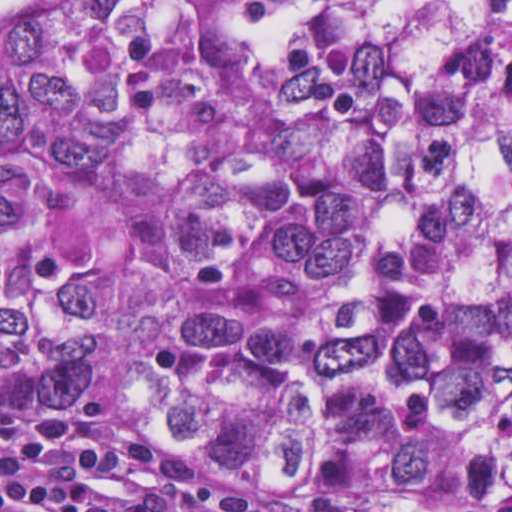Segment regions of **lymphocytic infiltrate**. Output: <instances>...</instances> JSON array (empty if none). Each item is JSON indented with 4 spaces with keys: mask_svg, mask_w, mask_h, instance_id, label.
Here are the masks:
<instances>
[{
    "mask_svg": "<svg viewBox=\"0 0 512 512\" xmlns=\"http://www.w3.org/2000/svg\"><path fill=\"white\" fill-rule=\"evenodd\" d=\"M0 512H400L203 469L122 398L0 411Z\"/></svg>",
    "mask_w": 512,
    "mask_h": 512,
    "instance_id": "1",
    "label": "lymphocytic infiltrate"
}]
</instances>
